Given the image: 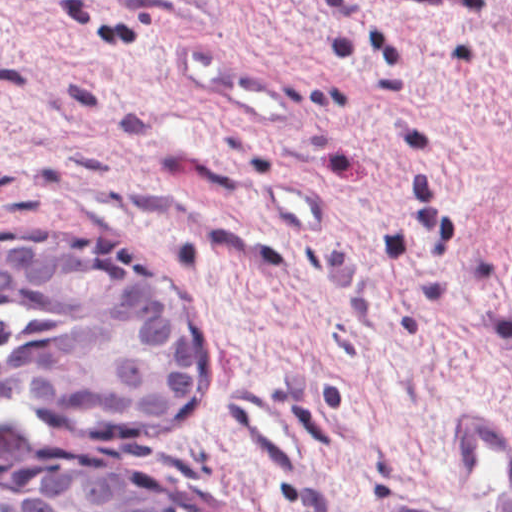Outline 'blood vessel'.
I'll return each instance as SVG.
<instances>
[{"instance_id":"8fb6f2fc","label":"blood vessel","mask_w":512,"mask_h":512,"mask_svg":"<svg viewBox=\"0 0 512 512\" xmlns=\"http://www.w3.org/2000/svg\"><path fill=\"white\" fill-rule=\"evenodd\" d=\"M171 62L186 81L264 124L296 123L292 98L268 75L217 46L202 31L181 33ZM266 174L256 186L281 236H323L331 209L293 173ZM398 512H512V434L471 407L454 424V471L446 494L399 503Z\"/></svg>"}]
</instances>
